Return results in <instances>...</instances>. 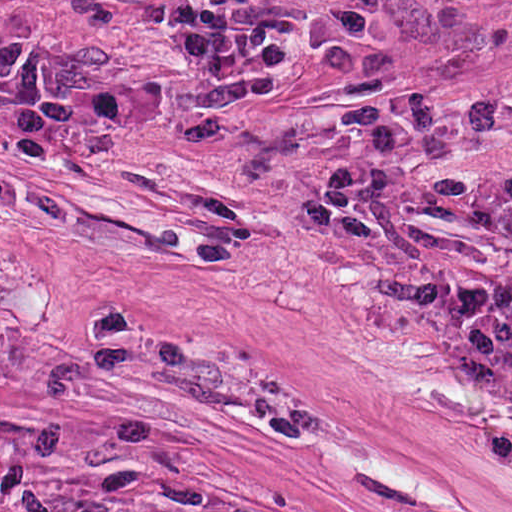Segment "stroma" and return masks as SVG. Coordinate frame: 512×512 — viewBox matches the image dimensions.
<instances>
[{
	"instance_id": "35a3bbf8",
	"label": "stroma",
	"mask_w": 512,
	"mask_h": 512,
	"mask_svg": "<svg viewBox=\"0 0 512 512\" xmlns=\"http://www.w3.org/2000/svg\"><path fill=\"white\" fill-rule=\"evenodd\" d=\"M174 101L0 106V324L512 490L510 432L304 217L337 171L512 214V0H0Z\"/></svg>"
}]
</instances>
